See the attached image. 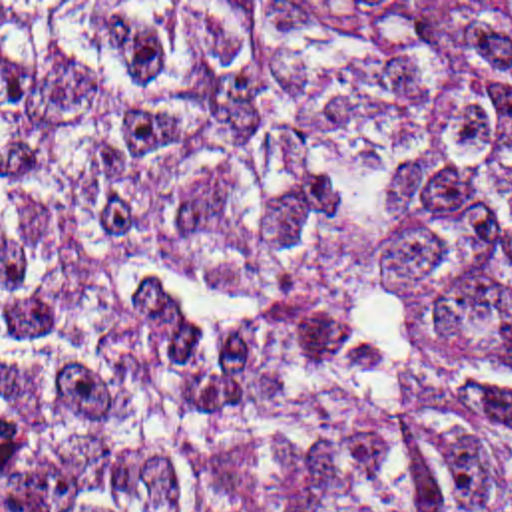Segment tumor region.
<instances>
[{
  "instance_id": "1",
  "label": "tumor region",
  "mask_w": 512,
  "mask_h": 512,
  "mask_svg": "<svg viewBox=\"0 0 512 512\" xmlns=\"http://www.w3.org/2000/svg\"><path fill=\"white\" fill-rule=\"evenodd\" d=\"M0 512H512V2H0Z\"/></svg>"
}]
</instances>
